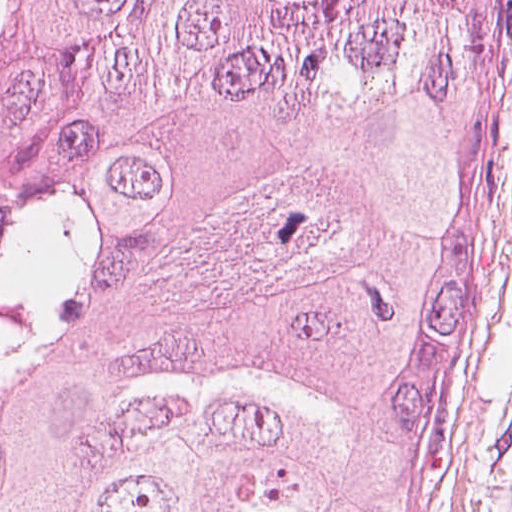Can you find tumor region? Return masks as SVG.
Masks as SVG:
<instances>
[{"instance_id":"e687c5a6","label":"tumor region","mask_w":512,"mask_h":512,"mask_svg":"<svg viewBox=\"0 0 512 512\" xmlns=\"http://www.w3.org/2000/svg\"><path fill=\"white\" fill-rule=\"evenodd\" d=\"M499 2L0 0V512H413Z\"/></svg>"}]
</instances>
